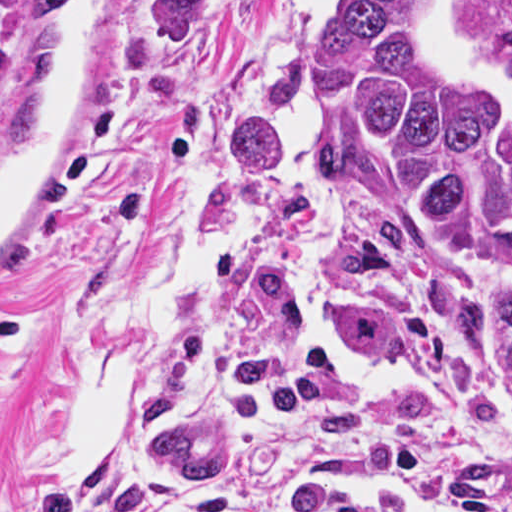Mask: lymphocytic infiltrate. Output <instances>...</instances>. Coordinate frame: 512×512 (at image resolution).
<instances>
[{"label": "lymphocytic infiltrate", "mask_w": 512, "mask_h": 512, "mask_svg": "<svg viewBox=\"0 0 512 512\" xmlns=\"http://www.w3.org/2000/svg\"><path fill=\"white\" fill-rule=\"evenodd\" d=\"M225 377L240 390L283 407L352 452L423 487L440 506L458 512H505L460 469L407 448L390 432L354 419L297 390L270 355L236 357ZM26 512H177L161 497H136L110 510L97 497L52 493ZM186 512H409L374 497L329 493L299 483L219 489Z\"/></svg>", "instance_id": "1"}]
</instances>
